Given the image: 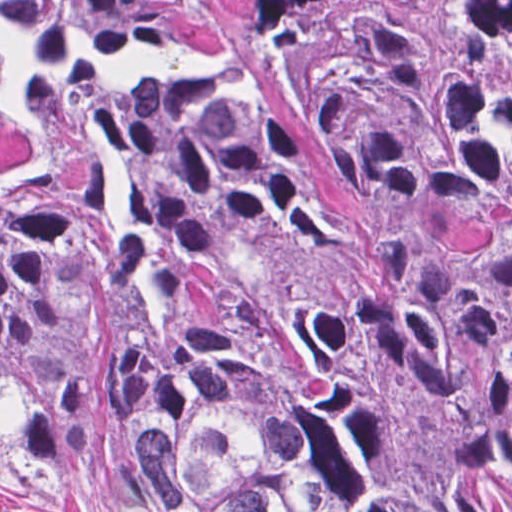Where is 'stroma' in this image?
Masks as SVG:
<instances>
[{"label": "stroma", "instance_id": "obj_1", "mask_svg": "<svg viewBox=\"0 0 512 512\" xmlns=\"http://www.w3.org/2000/svg\"><path fill=\"white\" fill-rule=\"evenodd\" d=\"M417 47L433 62L453 59L456 26L507 0H395ZM0 512H90L72 494L54 491L0 448Z\"/></svg>", "mask_w": 512, "mask_h": 512}]
</instances>
